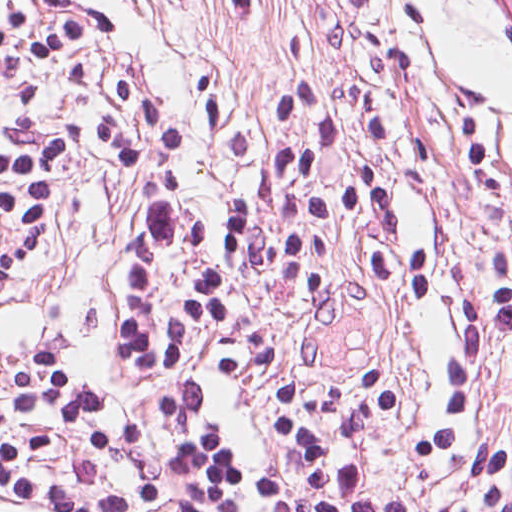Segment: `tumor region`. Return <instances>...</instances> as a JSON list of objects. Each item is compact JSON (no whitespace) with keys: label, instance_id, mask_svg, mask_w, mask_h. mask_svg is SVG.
Wrapping results in <instances>:
<instances>
[{"label":"tumor region","instance_id":"tumor-region-1","mask_svg":"<svg viewBox=\"0 0 512 512\" xmlns=\"http://www.w3.org/2000/svg\"><path fill=\"white\" fill-rule=\"evenodd\" d=\"M477 7L506 35L512 46V0H473Z\"/></svg>","mask_w":512,"mask_h":512}]
</instances>
